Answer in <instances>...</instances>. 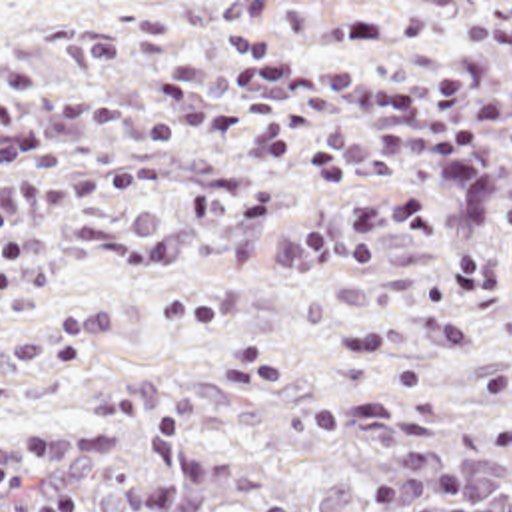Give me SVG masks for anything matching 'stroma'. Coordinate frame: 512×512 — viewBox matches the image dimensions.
<instances>
[{
  "label": "stroma",
  "mask_w": 512,
  "mask_h": 512,
  "mask_svg": "<svg viewBox=\"0 0 512 512\" xmlns=\"http://www.w3.org/2000/svg\"><path fill=\"white\" fill-rule=\"evenodd\" d=\"M512 405V0H0V425L98 391Z\"/></svg>",
  "instance_id": "35a3bbf8"
}]
</instances>
